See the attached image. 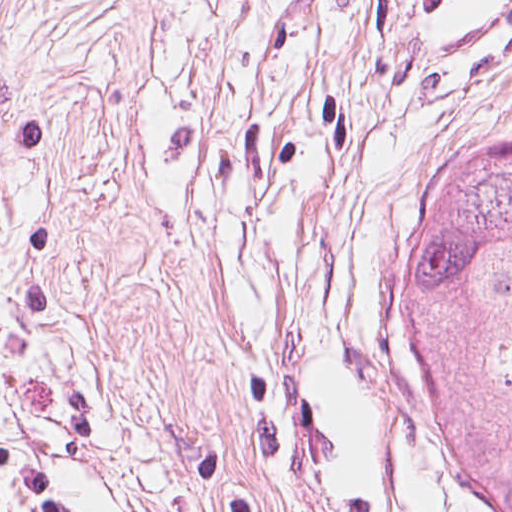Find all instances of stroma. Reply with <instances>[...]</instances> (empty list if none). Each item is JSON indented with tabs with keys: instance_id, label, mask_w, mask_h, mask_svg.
<instances>
[{
	"instance_id": "obj_1",
	"label": "stroma",
	"mask_w": 512,
	"mask_h": 512,
	"mask_svg": "<svg viewBox=\"0 0 512 512\" xmlns=\"http://www.w3.org/2000/svg\"><path fill=\"white\" fill-rule=\"evenodd\" d=\"M512 29L379 0H0V445L81 512H472L392 386L427 157Z\"/></svg>"
}]
</instances>
